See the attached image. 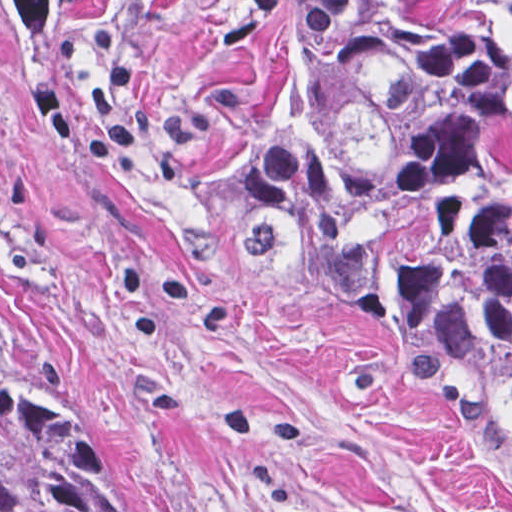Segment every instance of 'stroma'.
<instances>
[{"label": "stroma", "instance_id": "35a3bbf8", "mask_svg": "<svg viewBox=\"0 0 512 512\" xmlns=\"http://www.w3.org/2000/svg\"><path fill=\"white\" fill-rule=\"evenodd\" d=\"M330 1L70 0L34 51L0 4V291L131 418L175 512H512V448L240 232Z\"/></svg>", "mask_w": 512, "mask_h": 512}]
</instances>
